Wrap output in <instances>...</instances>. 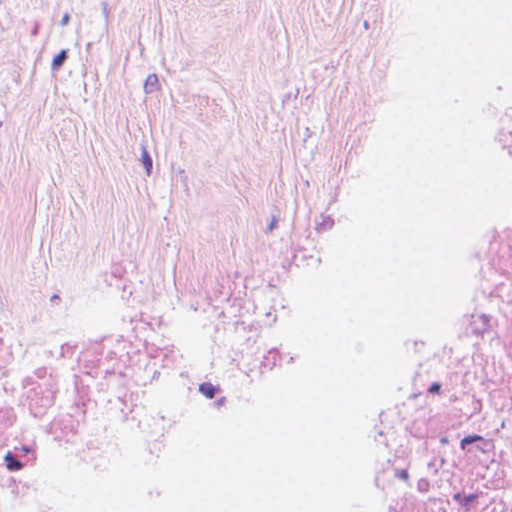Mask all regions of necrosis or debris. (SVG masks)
<instances>
[{
    "label": "necrosis or debris",
    "mask_w": 512,
    "mask_h": 512,
    "mask_svg": "<svg viewBox=\"0 0 512 512\" xmlns=\"http://www.w3.org/2000/svg\"><path fill=\"white\" fill-rule=\"evenodd\" d=\"M35 352L0 321V402ZM356 512H512V157L457 315L360 445Z\"/></svg>",
    "instance_id": "4bbe7bcc"
}]
</instances>
